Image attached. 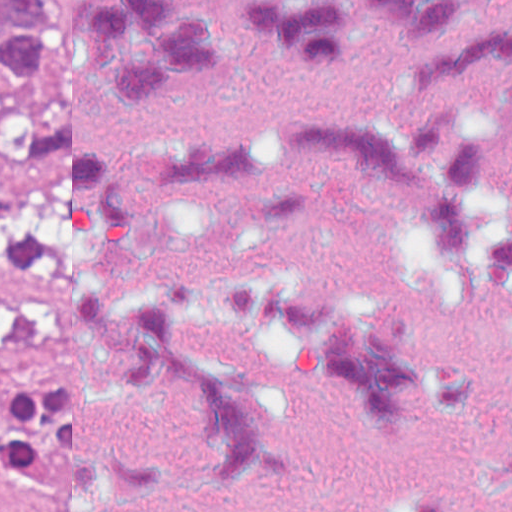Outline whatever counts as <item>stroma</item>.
Listing matches in <instances>:
<instances>
[{"mask_svg":"<svg viewBox=\"0 0 512 512\" xmlns=\"http://www.w3.org/2000/svg\"><path fill=\"white\" fill-rule=\"evenodd\" d=\"M52 61V60H51ZM44 89L0 114V408L29 384L62 386V298L45 194ZM0 512H56L0 463Z\"/></svg>","mask_w":512,"mask_h":512,"instance_id":"1","label":"stroma"}]
</instances>
